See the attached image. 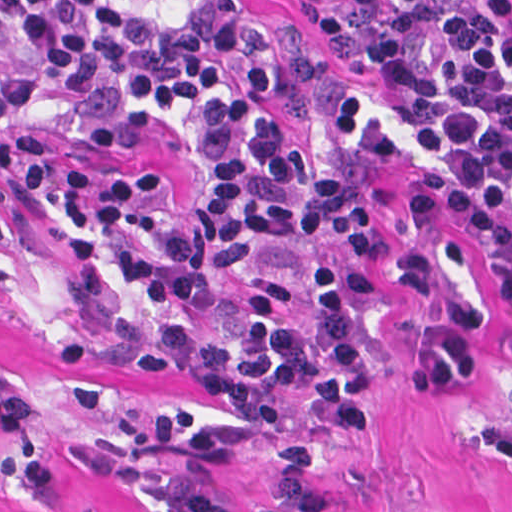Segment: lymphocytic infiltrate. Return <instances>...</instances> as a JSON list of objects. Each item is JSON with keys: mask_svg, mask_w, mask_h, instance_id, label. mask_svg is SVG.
<instances>
[{"mask_svg": "<svg viewBox=\"0 0 512 512\" xmlns=\"http://www.w3.org/2000/svg\"><path fill=\"white\" fill-rule=\"evenodd\" d=\"M359 81L321 78L313 135L292 141L269 109L278 37L245 0H0V184L51 265L105 311L57 369L69 405L104 402L93 368L193 380L228 408L116 400L83 452L149 512H232L216 466L275 464L259 512H328L310 490L314 447L267 418L280 388L352 440L369 420L374 294L430 311L415 380L464 386L478 340L473 269L429 238L383 244L361 194L368 172L410 156L417 214L476 229L512 292V0H291ZM103 149L151 132L194 170V202L162 180L106 168L52 141ZM6 227L0 208V239ZM241 305L239 321L166 309ZM25 409L0 368V427Z\"/></svg>", "mask_w": 512, "mask_h": 512, "instance_id": "obj_1", "label": "lymphocytic infiltrate"}]
</instances>
